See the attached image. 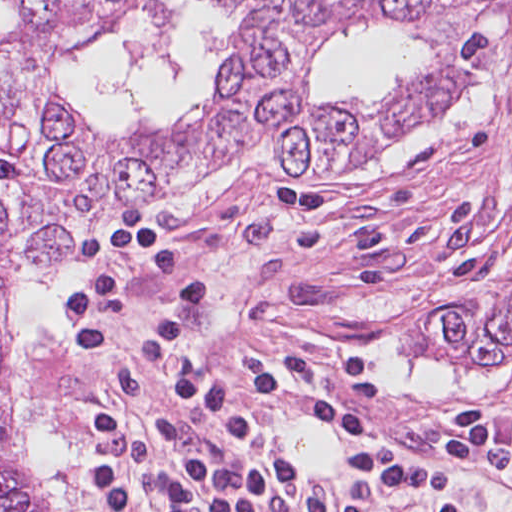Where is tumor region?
<instances>
[{
    "label": "tumor region",
    "mask_w": 512,
    "mask_h": 512,
    "mask_svg": "<svg viewBox=\"0 0 512 512\" xmlns=\"http://www.w3.org/2000/svg\"><path fill=\"white\" fill-rule=\"evenodd\" d=\"M128 0H0V512H51L22 478L7 403L8 329L24 272L57 267L91 217L185 184L222 154L264 141L289 171H326L383 137L451 113L510 50L512 0H231L252 32L232 46L198 125L169 140L116 141L77 115L54 65L79 51L102 7ZM378 22L420 35L438 69L414 89L347 105L302 91L304 43ZM431 332L474 366L512 362V300L440 304Z\"/></svg>",
    "instance_id": "obj_1"
}]
</instances>
